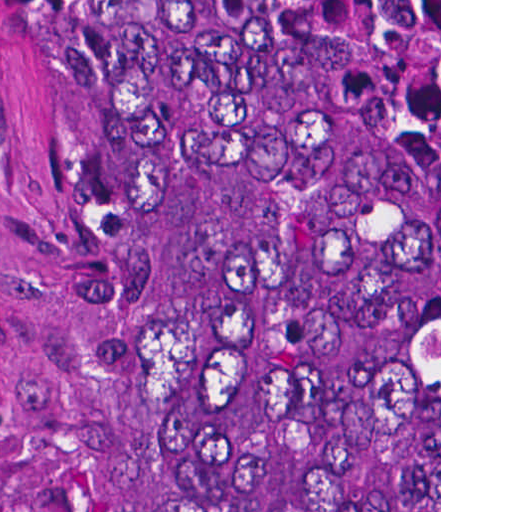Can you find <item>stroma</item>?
<instances>
[{
  "label": "stroma",
  "mask_w": 512,
  "mask_h": 512,
  "mask_svg": "<svg viewBox=\"0 0 512 512\" xmlns=\"http://www.w3.org/2000/svg\"><path fill=\"white\" fill-rule=\"evenodd\" d=\"M0 512H163L95 175L34 0H0Z\"/></svg>",
  "instance_id": "35a3bbf8"
}]
</instances>
